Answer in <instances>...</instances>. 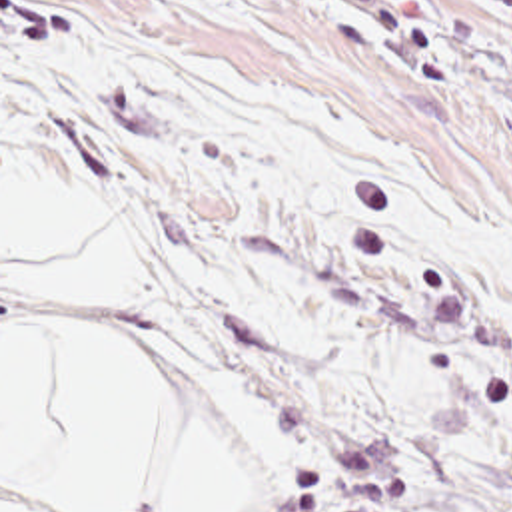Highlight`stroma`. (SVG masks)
<instances>
[{
  "label": "stroma",
  "instance_id": "35a3bbf8",
  "mask_svg": "<svg viewBox=\"0 0 512 512\" xmlns=\"http://www.w3.org/2000/svg\"><path fill=\"white\" fill-rule=\"evenodd\" d=\"M82 10L116 332L232 512H512V0Z\"/></svg>",
  "mask_w": 512,
  "mask_h": 512
}]
</instances>
